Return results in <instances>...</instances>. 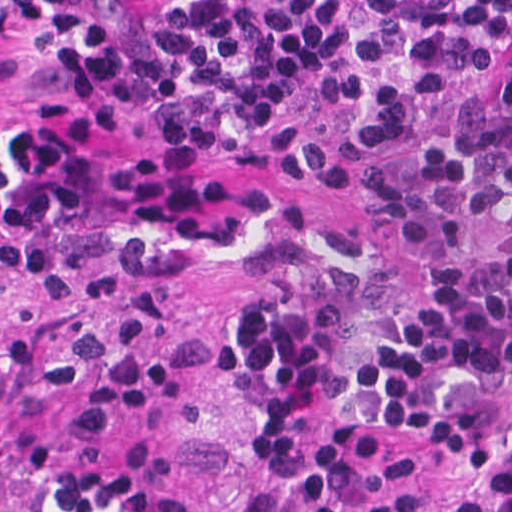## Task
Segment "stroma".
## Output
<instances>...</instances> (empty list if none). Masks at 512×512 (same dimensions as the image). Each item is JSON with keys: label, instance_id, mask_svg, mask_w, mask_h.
Instances as JSON below:
<instances>
[{"label": "stroma", "instance_id": "35a3bbf8", "mask_svg": "<svg viewBox=\"0 0 512 512\" xmlns=\"http://www.w3.org/2000/svg\"><path fill=\"white\" fill-rule=\"evenodd\" d=\"M84 1L113 21H143L169 0ZM42 85L25 43H0V104L27 111L43 102L36 93ZM144 297L171 299L206 329L214 368L116 436L158 443L175 459L202 512H294L296 475L270 471L232 387L242 355L235 317L270 300L260 266L224 245H94L1 287L0 317L114 314ZM506 453H512V430L451 439L430 451L422 466L425 483L445 496Z\"/></svg>", "mask_w": 512, "mask_h": 512}]
</instances>
